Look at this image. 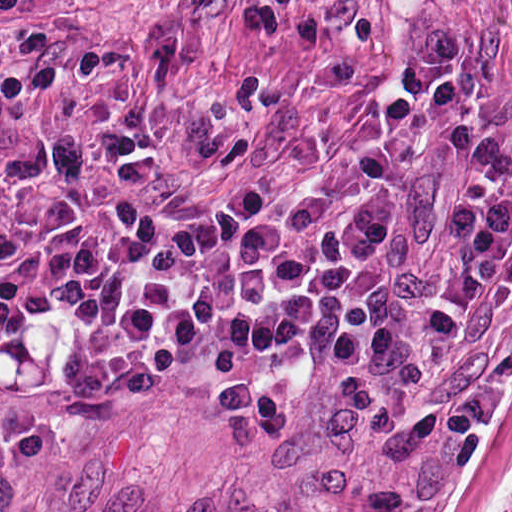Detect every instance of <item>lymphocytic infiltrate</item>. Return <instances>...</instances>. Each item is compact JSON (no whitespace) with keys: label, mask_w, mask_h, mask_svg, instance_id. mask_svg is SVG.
I'll return each instance as SVG.
<instances>
[{"label":"lymphocytic infiltrate","mask_w":512,"mask_h":512,"mask_svg":"<svg viewBox=\"0 0 512 512\" xmlns=\"http://www.w3.org/2000/svg\"><path fill=\"white\" fill-rule=\"evenodd\" d=\"M152 243L146 207L126 192L58 194L31 245L0 264V367L52 326L94 324L121 309Z\"/></svg>","instance_id":"lymphocytic-infiltrate-1"}]
</instances>
